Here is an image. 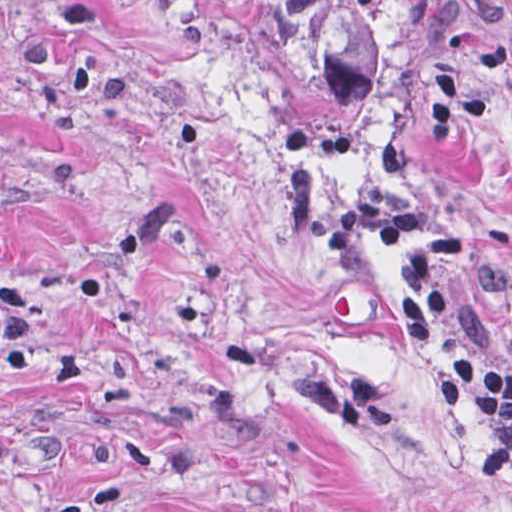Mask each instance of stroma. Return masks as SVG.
Wrapping results in <instances>:
<instances>
[{
  "label": "stroma",
  "instance_id": "1",
  "mask_svg": "<svg viewBox=\"0 0 512 512\" xmlns=\"http://www.w3.org/2000/svg\"><path fill=\"white\" fill-rule=\"evenodd\" d=\"M0 512H512L444 347L289 192L247 0H0Z\"/></svg>",
  "mask_w": 512,
  "mask_h": 512
}]
</instances>
